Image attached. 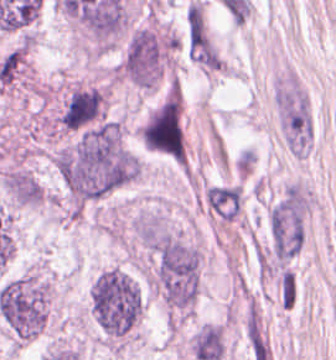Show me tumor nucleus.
I'll return each instance as SVG.
<instances>
[{"label": "tumor nucleus", "instance_id": "tumor-nucleus-4", "mask_svg": "<svg viewBox=\"0 0 336 360\" xmlns=\"http://www.w3.org/2000/svg\"><path fill=\"white\" fill-rule=\"evenodd\" d=\"M144 146L176 160L185 157L180 93H166L142 121L139 128Z\"/></svg>", "mask_w": 336, "mask_h": 360}, {"label": "tumor nucleus", "instance_id": "tumor-nucleus-3", "mask_svg": "<svg viewBox=\"0 0 336 360\" xmlns=\"http://www.w3.org/2000/svg\"><path fill=\"white\" fill-rule=\"evenodd\" d=\"M171 32L145 23L125 38L118 61L119 78L134 87L154 90L170 66Z\"/></svg>", "mask_w": 336, "mask_h": 360}, {"label": "tumor nucleus", "instance_id": "tumor-nucleus-1", "mask_svg": "<svg viewBox=\"0 0 336 360\" xmlns=\"http://www.w3.org/2000/svg\"><path fill=\"white\" fill-rule=\"evenodd\" d=\"M68 201L93 200L133 180L139 167L120 126L114 120L81 127L52 155Z\"/></svg>", "mask_w": 336, "mask_h": 360}, {"label": "tumor nucleus", "instance_id": "tumor-nucleus-2", "mask_svg": "<svg viewBox=\"0 0 336 360\" xmlns=\"http://www.w3.org/2000/svg\"><path fill=\"white\" fill-rule=\"evenodd\" d=\"M88 305L102 336L115 341L133 329L140 315V288L122 269L107 267L91 282Z\"/></svg>", "mask_w": 336, "mask_h": 360}]
</instances>
